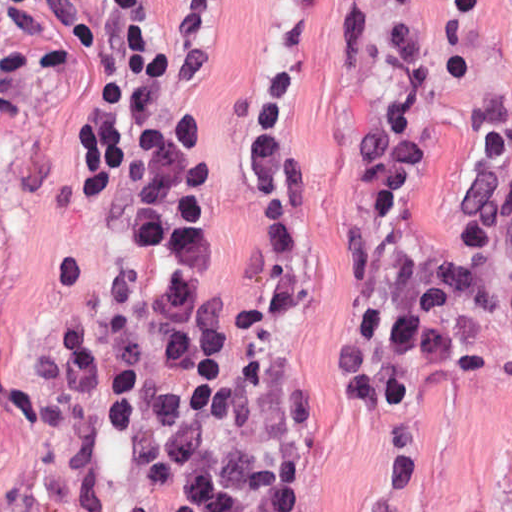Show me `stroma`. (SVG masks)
<instances>
[{"label": "stroma", "mask_w": 512, "mask_h": 512, "mask_svg": "<svg viewBox=\"0 0 512 512\" xmlns=\"http://www.w3.org/2000/svg\"><path fill=\"white\" fill-rule=\"evenodd\" d=\"M0 0V512H132L152 463L107 433L101 390H73L62 359L107 315L128 240L133 185L89 196L78 131L104 63L100 0L75 36L36 29ZM351 0H140L168 63L165 123L198 155L212 185L208 268L231 309L269 267L270 228L247 165L251 90L265 67H289L287 151L304 174L297 297L250 326L304 389L318 448L320 512H512L509 268L490 266L495 305L486 376H442L413 425L412 467L393 500L377 479V417L354 402L330 358L342 240L357 217L351 133L375 92L380 34L354 70L335 68ZM416 43L432 67L430 162L414 199L417 245L432 267L455 250L458 213L481 142L479 101L512 108V0H489L466 29L444 0H419Z\"/></svg>", "instance_id": "obj_1"}]
</instances>
